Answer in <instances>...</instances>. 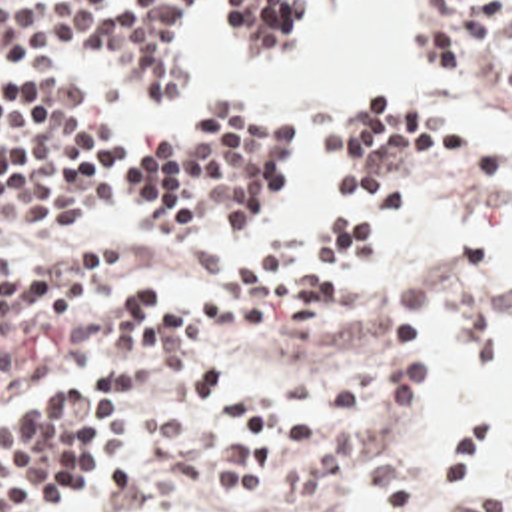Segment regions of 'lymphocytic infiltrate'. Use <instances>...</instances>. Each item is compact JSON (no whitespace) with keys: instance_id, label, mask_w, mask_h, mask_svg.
Here are the masks:
<instances>
[{"instance_id":"1","label":"lymphocytic infiltrate","mask_w":512,"mask_h":512,"mask_svg":"<svg viewBox=\"0 0 512 512\" xmlns=\"http://www.w3.org/2000/svg\"><path fill=\"white\" fill-rule=\"evenodd\" d=\"M205 2L0 0V235L53 215L205 231L247 215L291 155L289 121L193 105L161 133H143L119 103L129 93L183 95V39ZM317 2L335 0H217L209 35L241 55H283ZM427 39L512 101V0H427ZM389 107L357 103L323 127L311 225L279 263H255L235 241L163 249L81 235L0 273V401L73 369L121 371L171 347L335 351L363 275L449 189L457 165L455 129ZM121 443L123 405L101 391L1 429L0 512H57L69 489L101 481ZM435 459L443 483L461 487L455 512H512L487 421L445 419Z\"/></svg>"}]
</instances>
